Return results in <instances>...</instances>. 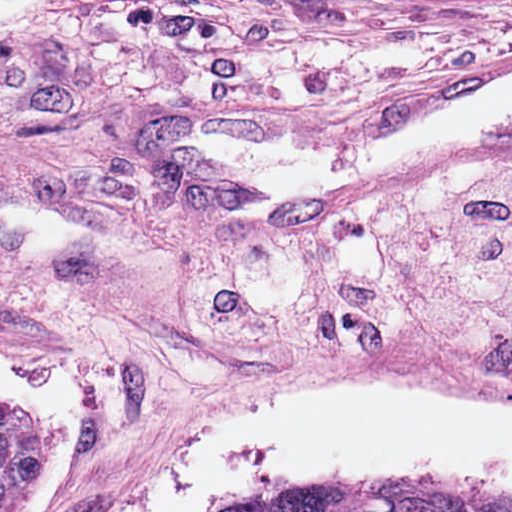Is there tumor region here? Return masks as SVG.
<instances>
[{
	"instance_id": "1",
	"label": "tumor region",
	"mask_w": 512,
	"mask_h": 512,
	"mask_svg": "<svg viewBox=\"0 0 512 512\" xmlns=\"http://www.w3.org/2000/svg\"><path fill=\"white\" fill-rule=\"evenodd\" d=\"M38 426L18 406L0 405V512H15ZM233 512H512V500L399 487L330 488Z\"/></svg>"
}]
</instances>
